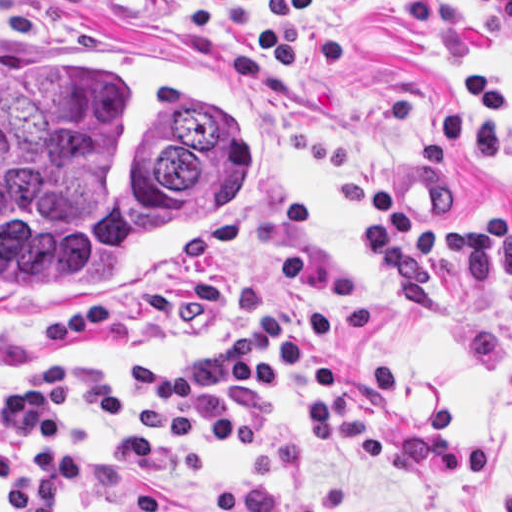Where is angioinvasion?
<instances>
[{
  "label": "angioinvasion",
  "mask_w": 512,
  "mask_h": 512,
  "mask_svg": "<svg viewBox=\"0 0 512 512\" xmlns=\"http://www.w3.org/2000/svg\"><path fill=\"white\" fill-rule=\"evenodd\" d=\"M263 92L72 0H0V324L97 314L232 264Z\"/></svg>",
  "instance_id": "1"
}]
</instances>
